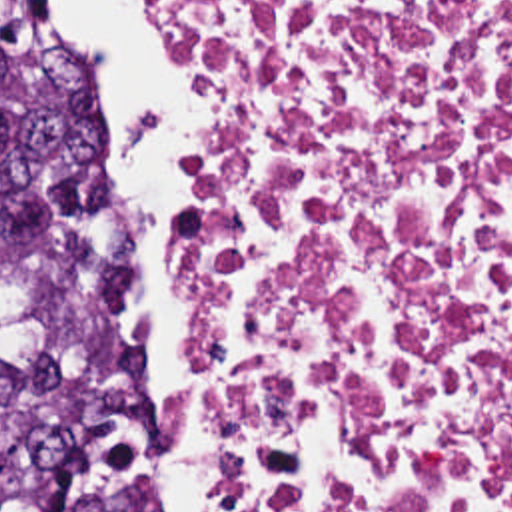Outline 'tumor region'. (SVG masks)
Segmentation results:
<instances>
[{
  "label": "tumor region",
  "instance_id": "obj_1",
  "mask_svg": "<svg viewBox=\"0 0 512 512\" xmlns=\"http://www.w3.org/2000/svg\"><path fill=\"white\" fill-rule=\"evenodd\" d=\"M138 326L100 84L40 0H0V512H154Z\"/></svg>",
  "mask_w": 512,
  "mask_h": 512
}]
</instances>
